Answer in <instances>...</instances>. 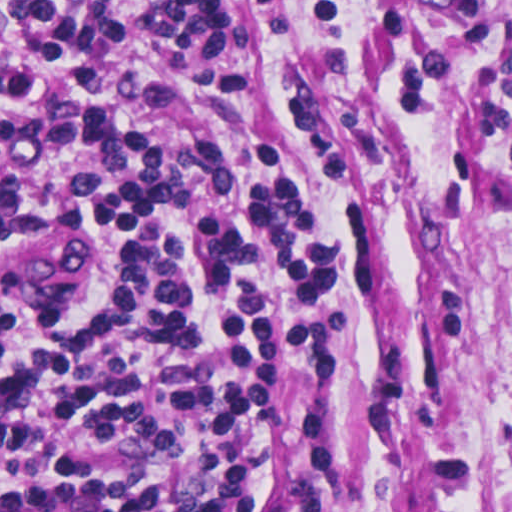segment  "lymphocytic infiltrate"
<instances>
[{
  "mask_svg": "<svg viewBox=\"0 0 512 512\" xmlns=\"http://www.w3.org/2000/svg\"><path fill=\"white\" fill-rule=\"evenodd\" d=\"M165 0L154 26L205 58L231 9ZM114 0H0V207H51L112 251L105 294L0 300V512H289L345 346L361 265L317 205L297 142L251 159L207 137L156 145L169 96L107 64ZM259 50L225 69L256 95ZM51 290V289H0Z\"/></svg>",
  "mask_w": 512,
  "mask_h": 512,
  "instance_id": "f902f5d3",
  "label": "lymphocytic infiltrate"
}]
</instances>
